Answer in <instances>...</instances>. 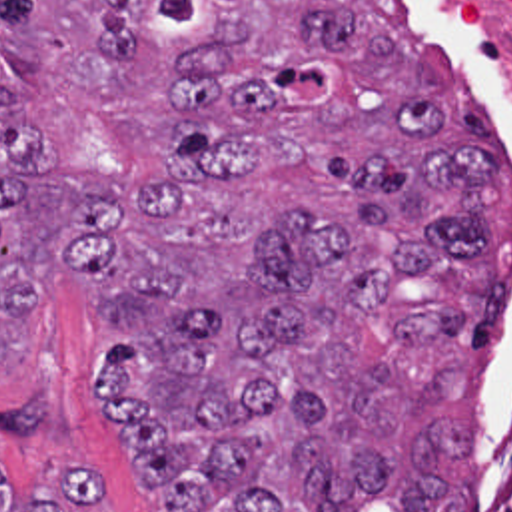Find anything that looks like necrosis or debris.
Masks as SVG:
<instances>
[{
	"label": "necrosis or debris",
	"instance_id": "necrosis-or-debris-1",
	"mask_svg": "<svg viewBox=\"0 0 512 512\" xmlns=\"http://www.w3.org/2000/svg\"><path fill=\"white\" fill-rule=\"evenodd\" d=\"M457 3L465 23L487 51L512 107V0ZM467 512H512V362L499 388Z\"/></svg>",
	"mask_w": 512,
	"mask_h": 512
}]
</instances>
